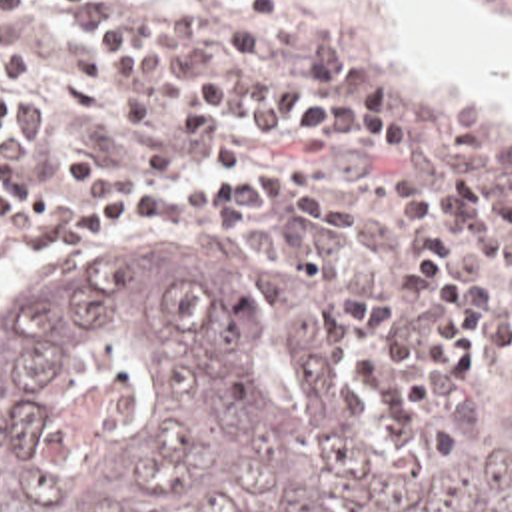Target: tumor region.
<instances>
[{
  "label": "tumor region",
  "mask_w": 512,
  "mask_h": 512,
  "mask_svg": "<svg viewBox=\"0 0 512 512\" xmlns=\"http://www.w3.org/2000/svg\"><path fill=\"white\" fill-rule=\"evenodd\" d=\"M254 232L78 256L0 302V512H512L506 376L450 458L440 412L376 440L326 318L258 328Z\"/></svg>",
  "instance_id": "obj_1"
}]
</instances>
